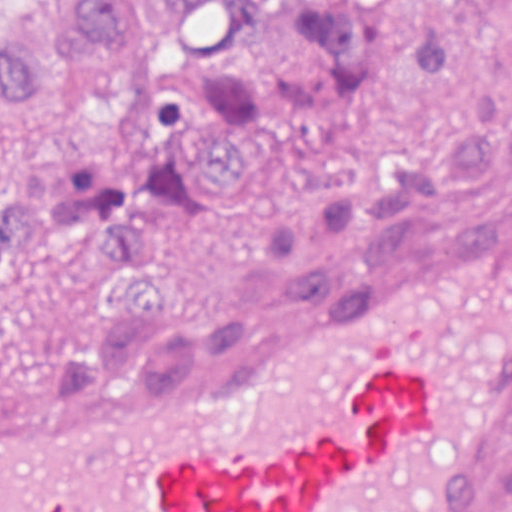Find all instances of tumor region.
<instances>
[{"instance_id": "e687c5a6", "label": "tumor region", "mask_w": 512, "mask_h": 512, "mask_svg": "<svg viewBox=\"0 0 512 512\" xmlns=\"http://www.w3.org/2000/svg\"><path fill=\"white\" fill-rule=\"evenodd\" d=\"M45 106L94 121L110 171L18 174L0 309L59 285L98 310L65 353L145 345L385 266L512 176V0H0V128ZM283 152H313L303 202L216 319L166 321L182 241ZM473 512H512V450Z\"/></svg>"}]
</instances>
